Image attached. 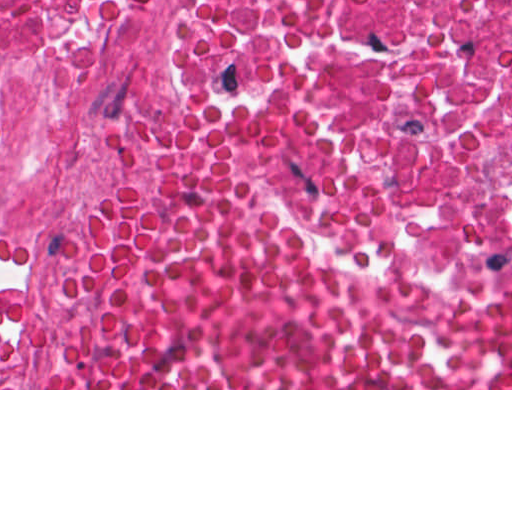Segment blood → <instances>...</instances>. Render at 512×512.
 Returning <instances> with one entry per match:
<instances>
[{"label":"blood","instance_id":"obj_1","mask_svg":"<svg viewBox=\"0 0 512 512\" xmlns=\"http://www.w3.org/2000/svg\"><path fill=\"white\" fill-rule=\"evenodd\" d=\"M53 317L62 388H512V306L357 303L239 126L203 113L138 139Z\"/></svg>","mask_w":512,"mask_h":512}]
</instances>
